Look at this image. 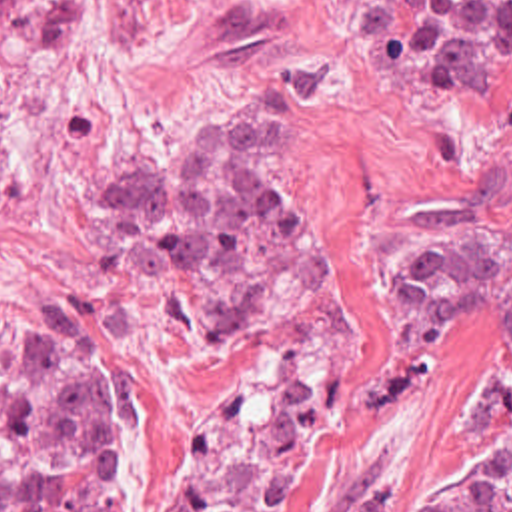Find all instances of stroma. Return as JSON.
I'll list each match as a JSON object with an SVG mask.
<instances>
[{
  "mask_svg": "<svg viewBox=\"0 0 512 512\" xmlns=\"http://www.w3.org/2000/svg\"><path fill=\"white\" fill-rule=\"evenodd\" d=\"M227 102L289 112L315 225L295 299L203 341L157 277L115 273L101 207L121 173ZM0 441L4 353L81 349L129 405V512H165L207 423L251 393L315 389V437L273 512H343L365 483L512 459V345L441 337L393 297L427 221L512 225V100H469L373 44V0H83L39 54L0 28ZM512 507V467L503 491Z\"/></svg>",
  "mask_w": 512,
  "mask_h": 512,
  "instance_id": "35a3bbf8",
  "label": "stroma"
}]
</instances>
